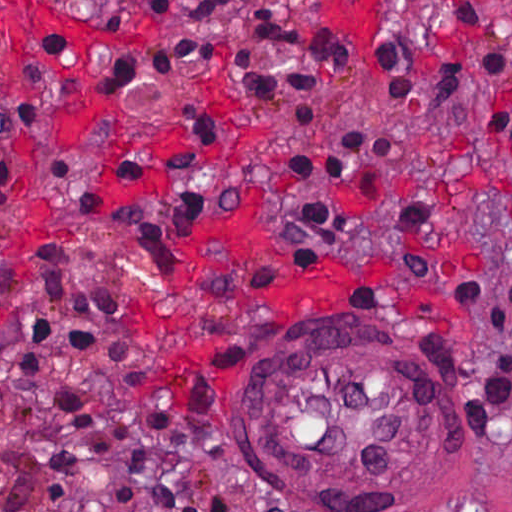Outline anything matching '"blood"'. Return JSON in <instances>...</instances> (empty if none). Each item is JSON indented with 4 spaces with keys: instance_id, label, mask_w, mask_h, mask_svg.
<instances>
[{
    "instance_id": "blood-1",
    "label": "blood",
    "mask_w": 512,
    "mask_h": 512,
    "mask_svg": "<svg viewBox=\"0 0 512 512\" xmlns=\"http://www.w3.org/2000/svg\"><path fill=\"white\" fill-rule=\"evenodd\" d=\"M0 5V36L9 42L8 74L17 98H32L26 82L30 59L38 58L51 69L52 59L45 47L51 35L65 34L79 58L95 45L138 47L147 43L116 28L55 12L44 0H0ZM225 257L240 263L241 286L286 308H342L354 281L390 279L389 270L383 266L370 277H359L343 267H293L282 261L271 246L260 217L231 215L199 235L170 275L143 297V308L162 339L154 379L171 398H181L182 389L204 369L207 346L194 322L171 317L170 303L183 297L196 278Z\"/></svg>"
}]
</instances>
